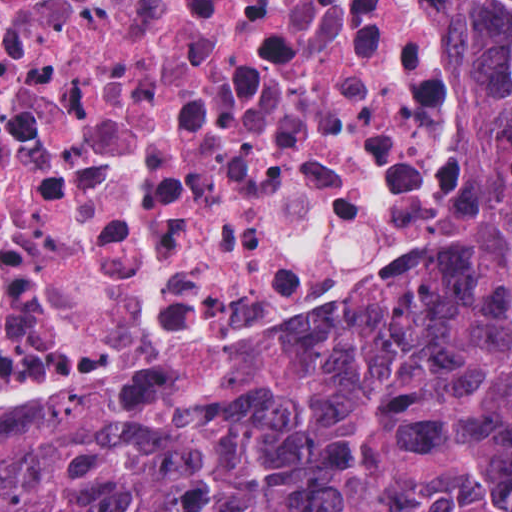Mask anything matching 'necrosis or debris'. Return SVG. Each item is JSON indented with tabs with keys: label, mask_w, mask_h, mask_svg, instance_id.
I'll use <instances>...</instances> for the list:
<instances>
[{
	"label": "necrosis or debris",
	"mask_w": 512,
	"mask_h": 512,
	"mask_svg": "<svg viewBox=\"0 0 512 512\" xmlns=\"http://www.w3.org/2000/svg\"><path fill=\"white\" fill-rule=\"evenodd\" d=\"M502 191L457 0H0V433L435 294Z\"/></svg>",
	"instance_id": "obj_1"
}]
</instances>
